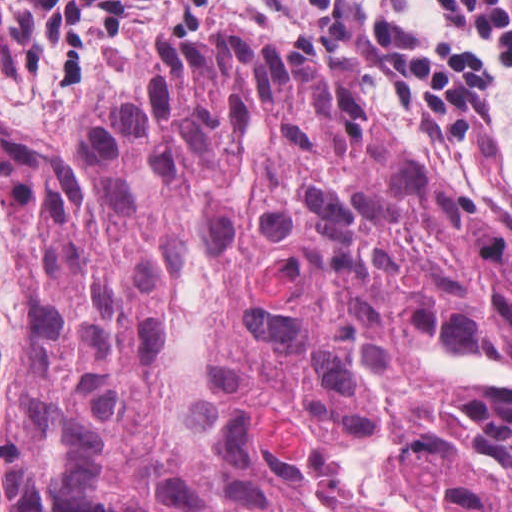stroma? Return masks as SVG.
<instances>
[{"label":"stroma","instance_id":"1","mask_svg":"<svg viewBox=\"0 0 512 512\" xmlns=\"http://www.w3.org/2000/svg\"><path fill=\"white\" fill-rule=\"evenodd\" d=\"M235 44L278 52L316 71L365 121L405 140L444 171L476 204L512 227V174L488 171L429 115L386 104L341 66L328 48L273 21H251L233 8L190 5L175 17L134 34L119 72L98 77L90 97L51 120H29L0 105V143L15 148H69L108 125L163 48ZM512 117V87L507 91ZM24 307L16 243L0 200V365L10 350ZM0 512H9L0 496Z\"/></svg>","mask_w":512,"mask_h":512}]
</instances>
